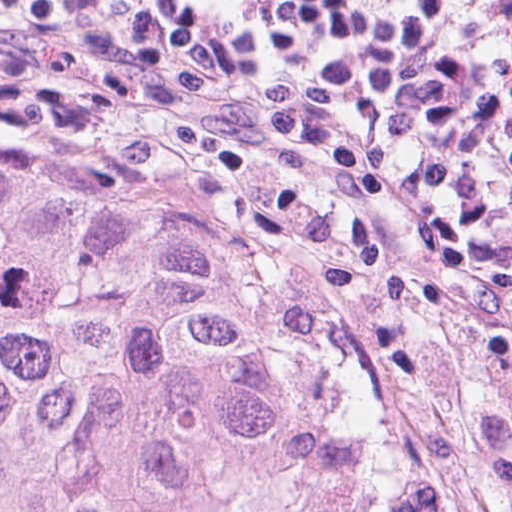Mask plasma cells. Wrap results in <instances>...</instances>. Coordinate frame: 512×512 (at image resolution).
<instances>
[{"label":"plasma cells","instance_id":"9512152a","mask_svg":"<svg viewBox=\"0 0 512 512\" xmlns=\"http://www.w3.org/2000/svg\"><path fill=\"white\" fill-rule=\"evenodd\" d=\"M0 41L158 74L424 277L512 279V0H0Z\"/></svg>","mask_w":512,"mask_h":512}]
</instances>
